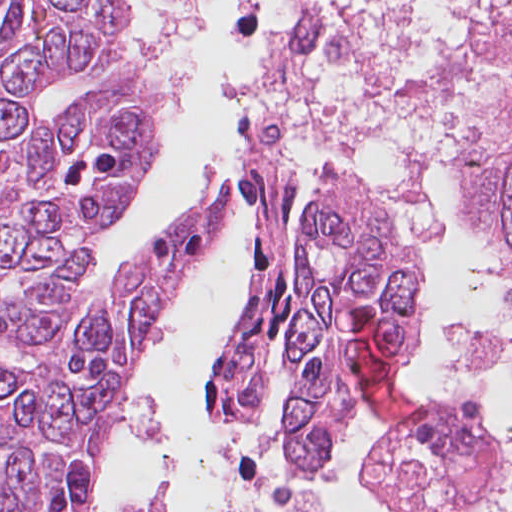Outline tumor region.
Listing matches in <instances>:
<instances>
[{
  "label": "tumor region",
  "mask_w": 512,
  "mask_h": 512,
  "mask_svg": "<svg viewBox=\"0 0 512 512\" xmlns=\"http://www.w3.org/2000/svg\"><path fill=\"white\" fill-rule=\"evenodd\" d=\"M311 212L351 334L358 308L369 306L393 333L402 363L420 345L413 248L351 185L319 182ZM480 220L488 239L512 253V95L491 146Z\"/></svg>",
  "instance_id": "1"
}]
</instances>
